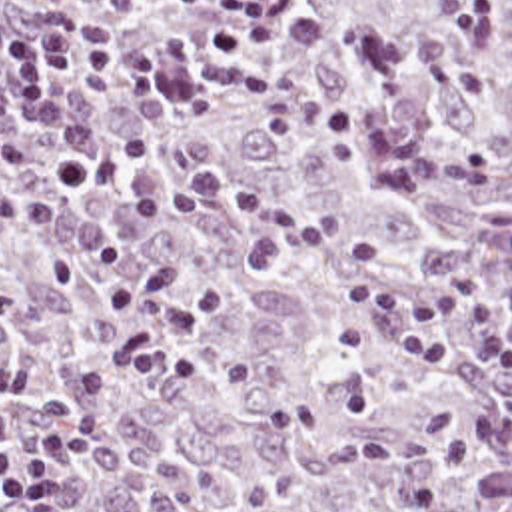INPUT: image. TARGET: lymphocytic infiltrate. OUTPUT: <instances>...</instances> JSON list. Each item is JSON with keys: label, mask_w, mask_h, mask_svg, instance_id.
Masks as SVG:
<instances>
[{"label": "lymphocytic infiltrate", "mask_w": 512, "mask_h": 512, "mask_svg": "<svg viewBox=\"0 0 512 512\" xmlns=\"http://www.w3.org/2000/svg\"><path fill=\"white\" fill-rule=\"evenodd\" d=\"M115 10L143 0H103ZM201 10L207 0H175ZM280 0H227L209 42L217 56L234 58L276 40ZM0 66L17 94L41 154L47 188L109 186L121 168L101 144L67 90L71 78L101 84L121 98H155L161 60L149 48H117L83 38L75 6L41 0H0ZM19 152L5 130L0 100V172L17 166ZM230 208L250 218L240 250L256 272L286 256H300L330 272L348 292L352 310L334 326L344 358L386 348L434 368L458 360L462 328L480 360L512 370V288L490 274H470L438 286L396 288L378 270L372 242L348 232L332 216H304L240 190L217 174H195L171 192L125 208L135 222H181L205 210ZM113 396L111 372L91 368L75 402H43L33 426L15 431L13 412L0 408V512H67V475Z\"/></svg>", "instance_id": "1"}]
</instances>
